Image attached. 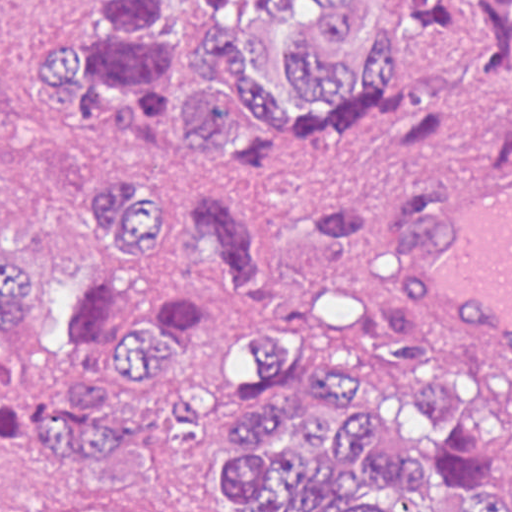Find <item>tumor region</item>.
I'll list each match as a JSON object with an SVG mask.
<instances>
[{
    "label": "tumor region",
    "instance_id": "obj_1",
    "mask_svg": "<svg viewBox=\"0 0 512 512\" xmlns=\"http://www.w3.org/2000/svg\"><path fill=\"white\" fill-rule=\"evenodd\" d=\"M32 87L100 140L80 223L85 281L59 301L64 383L19 413L30 464L205 512L187 455L211 415L183 385L238 303L270 304L273 260L300 245L291 308L245 325L248 400L226 422L214 498L232 512H512V376L460 381L368 258L415 197L406 170L382 227L348 202L273 231L261 191L211 167L246 136H337L397 124L392 152L465 131L474 100L512 89V0H77ZM487 169H512V115ZM358 381L362 405L354 387ZM402 448H385L378 434Z\"/></svg>",
    "mask_w": 512,
    "mask_h": 512
}]
</instances>
